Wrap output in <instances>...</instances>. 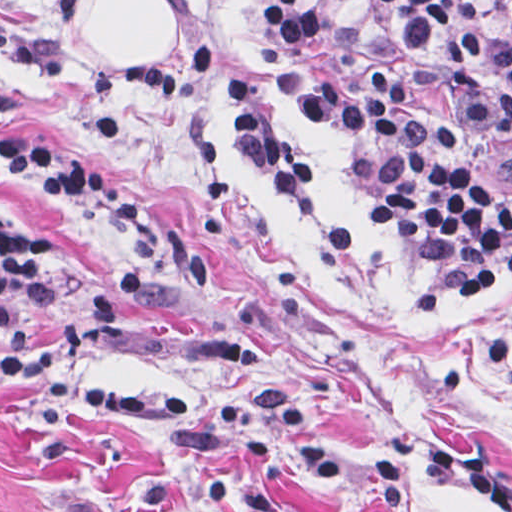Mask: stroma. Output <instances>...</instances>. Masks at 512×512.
Here are the masks:
<instances>
[{
  "mask_svg": "<svg viewBox=\"0 0 512 512\" xmlns=\"http://www.w3.org/2000/svg\"><path fill=\"white\" fill-rule=\"evenodd\" d=\"M332 64L409 72L467 171L512 185V144L446 119L440 72L375 0H321ZM177 55L204 42L253 79L318 173V195L256 179L198 94L171 110L116 76L76 22L49 24L59 72L0 56V146L65 144L156 225L147 246L9 173L0 199L39 222L88 285L0 337V512H512V272L424 309L448 260L370 221L413 182L371 126L330 129L259 76L271 0H163ZM487 39L493 0H460ZM41 0H0L19 32Z\"/></svg>",
  "mask_w": 512,
  "mask_h": 512,
  "instance_id": "35a3bbf8",
  "label": "stroma"
}]
</instances>
